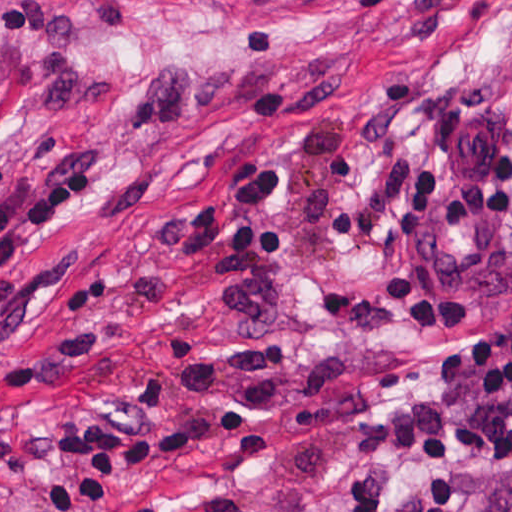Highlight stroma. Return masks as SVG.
<instances>
[{"mask_svg":"<svg viewBox=\"0 0 512 512\" xmlns=\"http://www.w3.org/2000/svg\"><path fill=\"white\" fill-rule=\"evenodd\" d=\"M0 188L95 170L97 197L14 260L84 252L116 271L110 333L0 411V512H335L409 464L405 402L434 356L512 313V211L425 233L434 272L479 303L461 329H407L386 294L398 208L429 110L512 53V0H0ZM279 154L285 313L244 327L229 257L184 264L156 230L231 157ZM512 121L455 149L447 189L491 192ZM453 512L512 468L460 460Z\"/></svg>","mask_w":512,"mask_h":512,"instance_id":"1","label":"stroma"}]
</instances>
